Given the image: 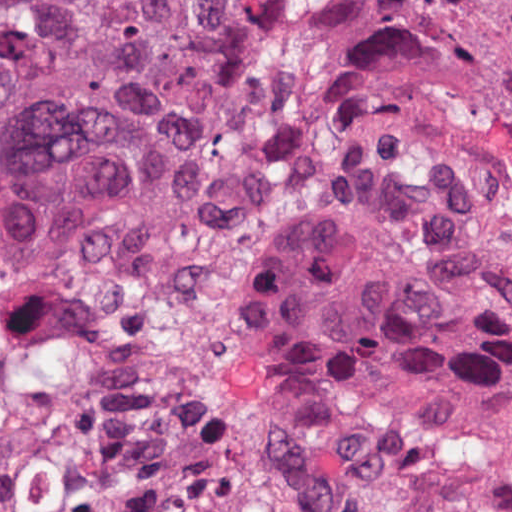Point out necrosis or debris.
I'll return each mask as SVG.
<instances>
[{
  "label": "necrosis or debris",
  "mask_w": 512,
  "mask_h": 512,
  "mask_svg": "<svg viewBox=\"0 0 512 512\" xmlns=\"http://www.w3.org/2000/svg\"><path fill=\"white\" fill-rule=\"evenodd\" d=\"M312 197L0 272V512H397L263 455L245 310Z\"/></svg>",
  "instance_id": "obj_1"
}]
</instances>
